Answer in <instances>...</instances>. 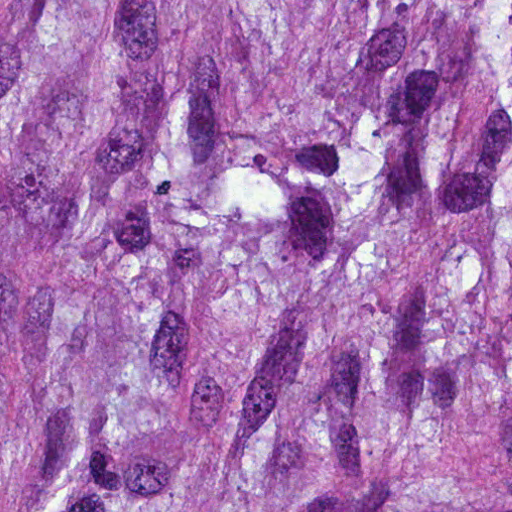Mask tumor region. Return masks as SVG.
I'll use <instances>...</instances> for the list:
<instances>
[{
  "mask_svg": "<svg viewBox=\"0 0 512 512\" xmlns=\"http://www.w3.org/2000/svg\"><path fill=\"white\" fill-rule=\"evenodd\" d=\"M0 512H512V0H0Z\"/></svg>",
  "mask_w": 512,
  "mask_h": 512,
  "instance_id": "1",
  "label": "tumor region"
}]
</instances>
